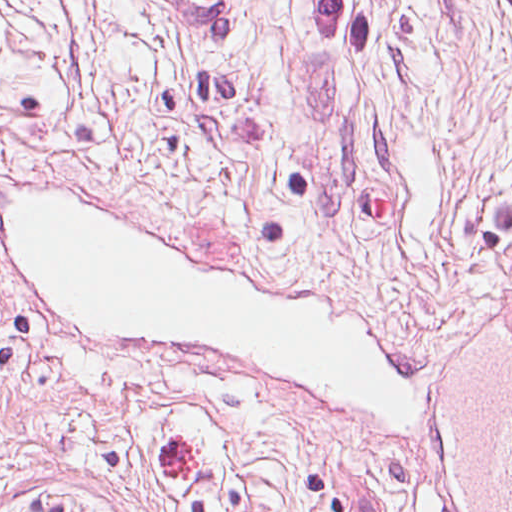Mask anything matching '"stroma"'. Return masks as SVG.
<instances>
[{"instance_id":"35a3bbf8","label":"stroma","mask_w":512,"mask_h":512,"mask_svg":"<svg viewBox=\"0 0 512 512\" xmlns=\"http://www.w3.org/2000/svg\"><path fill=\"white\" fill-rule=\"evenodd\" d=\"M78 198L198 267L293 285L417 394L379 422L214 349L56 318L0 240V512H435L450 334L512 295V0H0V238Z\"/></svg>"}]
</instances>
